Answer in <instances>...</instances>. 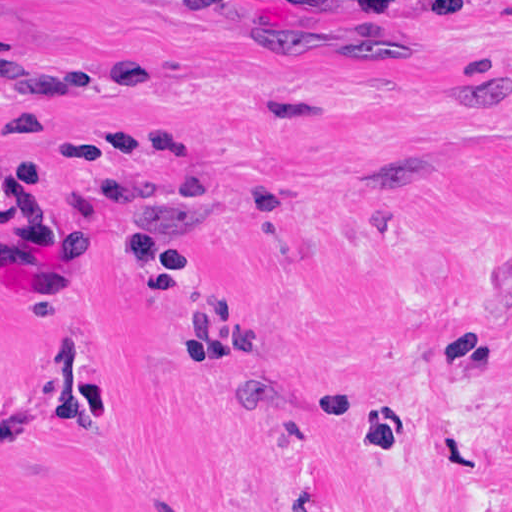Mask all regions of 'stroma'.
Listing matches in <instances>:
<instances>
[{
  "mask_svg": "<svg viewBox=\"0 0 512 512\" xmlns=\"http://www.w3.org/2000/svg\"><path fill=\"white\" fill-rule=\"evenodd\" d=\"M0 512H512V0H0Z\"/></svg>",
  "mask_w": 512,
  "mask_h": 512,
  "instance_id": "35a3bbf8",
  "label": "stroma"
}]
</instances>
